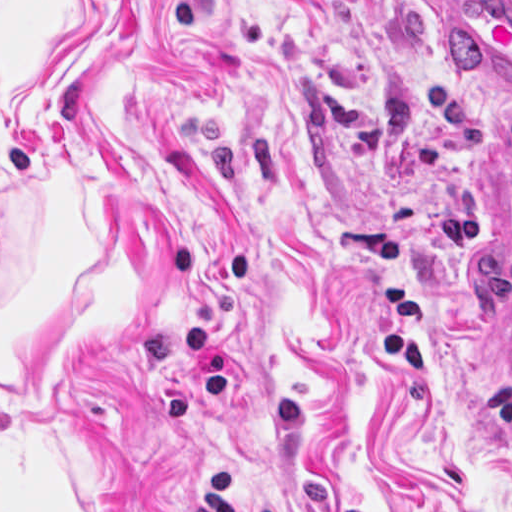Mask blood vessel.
<instances>
[{"mask_svg":"<svg viewBox=\"0 0 512 512\" xmlns=\"http://www.w3.org/2000/svg\"><path fill=\"white\" fill-rule=\"evenodd\" d=\"M477 208L502 309V374L512 380V132L494 136L482 154Z\"/></svg>","mask_w":512,"mask_h":512,"instance_id":"blood-vessel-1","label":"blood vessel"}]
</instances>
